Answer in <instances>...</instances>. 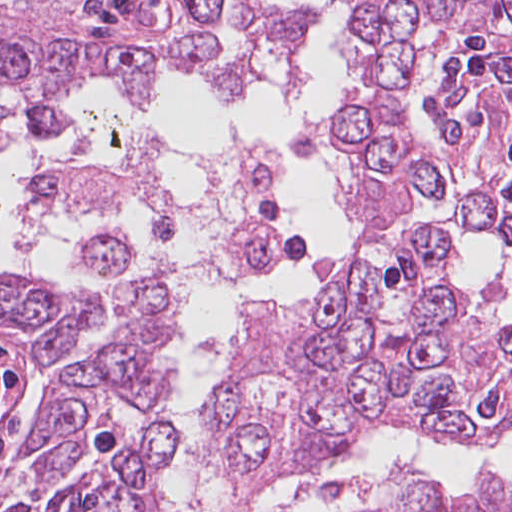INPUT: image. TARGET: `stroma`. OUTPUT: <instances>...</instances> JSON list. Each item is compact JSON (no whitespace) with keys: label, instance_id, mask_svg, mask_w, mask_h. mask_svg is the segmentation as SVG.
<instances>
[{"label":"stroma","instance_id":"1","mask_svg":"<svg viewBox=\"0 0 512 512\" xmlns=\"http://www.w3.org/2000/svg\"><path fill=\"white\" fill-rule=\"evenodd\" d=\"M349 178V177H348ZM346 178V181L348 180ZM352 211L357 216L358 221L362 225L363 229L364 226L362 224L361 216L357 208L350 207ZM418 209H416L417 212ZM437 210L444 215L448 216L457 226V215L454 210L450 208H441V209H434ZM248 221H261L267 225H269L272 229H274L281 238V249L276 256V258L273 260V262L269 265V267L260 273L245 276L249 278H255V277H262L269 275L271 272H273L278 264L281 261L283 249L285 246V235L280 227L279 223L274 222L272 220L263 218V217H253L247 219ZM245 222V223H246ZM244 223V224H245ZM235 235L230 239V241L226 244L228 246L230 242L233 240ZM225 246V247H226ZM224 247V248H225ZM220 251V250H219ZM217 253V252H216ZM214 253V254H216ZM214 254L201 257V258H195L188 261H184L181 263H177L170 266H158L155 268H151L139 273H136L134 275H131L127 277L126 279L122 280L119 284L118 289L132 283L138 280H141L153 273L157 272H163V271H169V270H184L188 268H192L206 260H208L210 257H212ZM455 268H456V262H455ZM456 272L461 277V279L464 281V283L467 285V287L470 288H485L480 285L473 284L467 280H465L462 275L459 273V271L456 268ZM223 277V276H220ZM40 279L46 280L43 276L39 277ZM219 278V277H218ZM204 281H200L196 284H194L190 290H194L198 285H200ZM189 292V293H190ZM189 295V294H188ZM285 303L290 308H296L304 301L302 300H285L281 301ZM498 311L500 314L504 317H511L512 314H510L508 311H506L504 308H501L497 304ZM111 328V316L108 320V322L103 325L101 328L96 325L94 337L97 341V343L106 335V333ZM162 383H151L147 389V393H150L155 388H157ZM49 386L48 380L46 378V375L44 373L42 365L36 364L29 348V343L26 334L16 325H4L0 324V479L4 475L12 457H13V444L15 440V435L17 432V428L19 425V422L25 412L34 404V402L37 400L39 395L42 393V391ZM420 433V432H419ZM427 436L445 440V441H451V442H460V443H469L466 442L460 438H454V437H446V436H439V435H432V434H426L422 433ZM512 438V428L511 430L501 437L500 439L489 442V443H496V442H502L507 441ZM473 444V443H470ZM176 445V442H175ZM175 445L167 452L163 463L161 467V472L159 476V481L161 488L169 495V497L172 499L173 502L180 505L184 509H186L188 512H199L196 510L189 509L181 504H179L175 498L171 495L168 487H167V480H166V473L175 449ZM363 448V447H362ZM360 448L355 454L350 456L349 458L339 462L335 467H333L329 472L336 471L339 469H343L346 466H348L350 463L353 462V460L356 458L359 451L362 449ZM210 461V460H209ZM211 466L214 471H216L219 475H221L223 478L231 481L235 487L245 493H259L271 489H250L245 486L237 485L233 479H231L228 475H226L216 464L211 462ZM328 473V472H327ZM318 477V476H316ZM314 477V478H316ZM479 476H475L472 478H468L465 481H463L461 484L456 486L455 488L461 492L464 490H467L471 487V485L478 479ZM313 479V478H312ZM302 481H294L291 483H288L286 485L280 486H288L291 484H295ZM278 487V488H280ZM346 496L349 498L351 502H353L355 505H357L359 512H363L357 499L352 493L344 492ZM205 512H215V511H205Z\"/></svg>","mask_w":512,"mask_h":512}]
</instances>
